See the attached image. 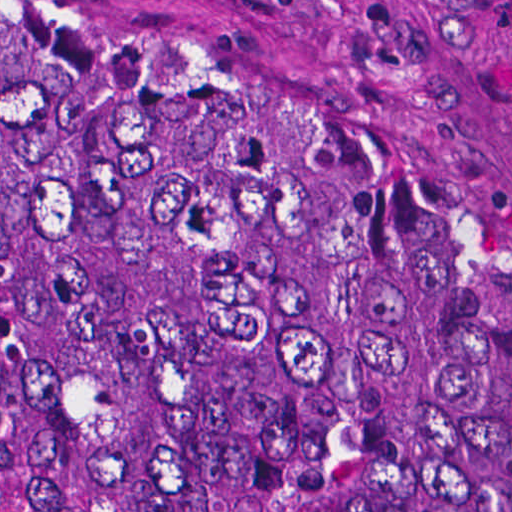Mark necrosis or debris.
<instances>
[{
  "label": "necrosis or debris",
  "mask_w": 512,
  "mask_h": 512,
  "mask_svg": "<svg viewBox=\"0 0 512 512\" xmlns=\"http://www.w3.org/2000/svg\"><path fill=\"white\" fill-rule=\"evenodd\" d=\"M0 512H19L9 500L0 481Z\"/></svg>",
  "instance_id": "4bbe7bcc"
}]
</instances>
